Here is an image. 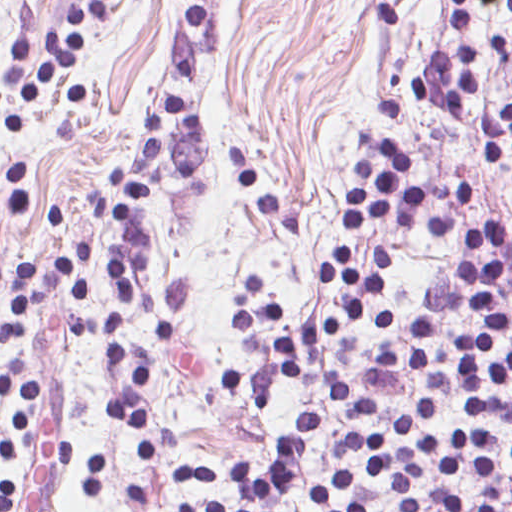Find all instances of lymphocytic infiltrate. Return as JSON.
Returning <instances> with one entry per match:
<instances>
[{
	"instance_id": "f902f5d3",
	"label": "lymphocytic infiltrate",
	"mask_w": 512,
	"mask_h": 512,
	"mask_svg": "<svg viewBox=\"0 0 512 512\" xmlns=\"http://www.w3.org/2000/svg\"><path fill=\"white\" fill-rule=\"evenodd\" d=\"M147 3L155 0H143ZM189 37H209L211 0H193ZM452 17V54L443 52L425 69L413 74L411 87L444 116H469L481 93L483 47L471 16L475 8L493 7L512 22V0H436ZM125 0H69L66 32L52 29L34 38L33 4L19 9L6 53L2 87L10 97L39 101L57 79H66V102L87 103L92 94L86 74L90 28L119 16ZM144 135L141 157L114 166L112 188L92 192V205L114 233L106 261L108 308L104 316L87 317L91 298L89 274L93 245H71L57 274L69 290L60 302L67 311L59 317L63 338L74 340L95 330L103 343L120 390L101 402L109 424L133 437L145 462L156 454L151 403L145 384L151 362L131 356L125 339L130 307L141 310L153 337L173 345L177 323L191 306L189 283L166 279L159 287L136 282L134 273L151 262V225L143 208L178 179H191L210 145V128L197 97L178 89L156 91L141 119ZM484 164L508 172L512 180V101L484 109L478 119ZM476 139V142H477ZM413 154L381 136L350 167L339 228L341 236L357 232L371 220L392 222L411 232L443 237L465 250H490L504 242L500 223H477L468 228L453 216H430L427 196L410 183L407 173ZM356 241L344 246L334 262L322 267L320 278L335 294V307L307 328H295L289 306L271 295V281L238 279L235 311L250 365L228 369L227 389L251 408L266 405L277 383L295 380L312 352L360 333H384L403 326V314L380 310L369 315L374 300L386 295L390 282L384 247H371L359 263ZM508 263L498 257L465 259L456 279L426 285L420 294V316L410 332L408 362L414 372H427L435 338L445 325L477 316L481 326L464 331L435 366L432 394L453 398L461 394L469 412L512 418V349L496 361L491 352L508 335V322L496 304L498 269ZM45 303L35 264L14 260L10 269V309L0 318V344H15L29 331L30 310ZM378 407L361 388L331 387L327 407L310 417L303 437L284 447L267 470L252 468L238 457L231 465L204 467L170 462V484L192 490L199 486H231L240 503L228 505L198 497L185 512H282L304 454L329 412L374 418ZM438 404L427 399L409 409L399 429L370 435L347 433L333 448V482L308 494L316 501L312 512H374L378 483L391 485V498L402 512H512V475L492 463L488 433L462 425L420 439L411 449L396 444L413 434L419 423L436 417ZM512 452V450H511ZM18 462V448L0 423V465ZM0 512H14L12 481L0 484Z\"/></svg>"
}]
</instances>
